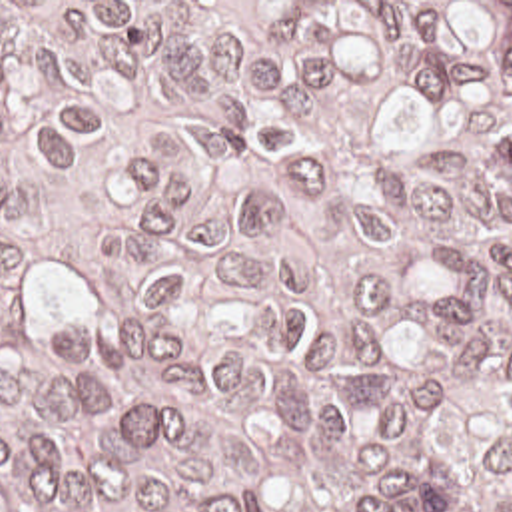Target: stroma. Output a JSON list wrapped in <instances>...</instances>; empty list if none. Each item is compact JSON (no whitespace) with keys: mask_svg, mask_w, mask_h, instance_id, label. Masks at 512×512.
Here are the masks:
<instances>
[{"mask_svg":"<svg viewBox=\"0 0 512 512\" xmlns=\"http://www.w3.org/2000/svg\"><path fill=\"white\" fill-rule=\"evenodd\" d=\"M0 2H259L265 10L273 2H512V0H0Z\"/></svg>","mask_w":512,"mask_h":512,"instance_id":"obj_1","label":"stroma"}]
</instances>
